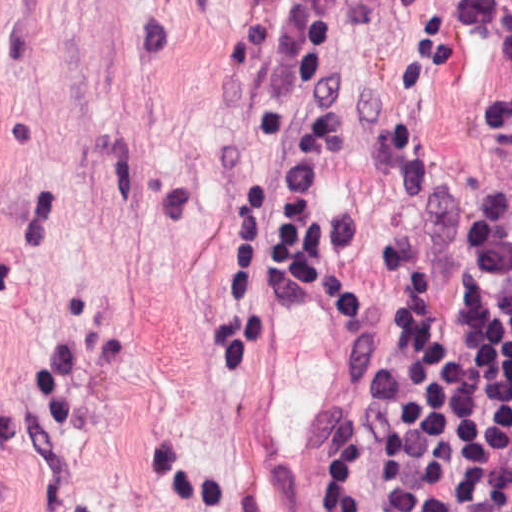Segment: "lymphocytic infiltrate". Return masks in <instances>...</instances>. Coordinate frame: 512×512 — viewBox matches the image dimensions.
<instances>
[{"label":"lymphocytic infiltrate","mask_w":512,"mask_h":512,"mask_svg":"<svg viewBox=\"0 0 512 512\" xmlns=\"http://www.w3.org/2000/svg\"><path fill=\"white\" fill-rule=\"evenodd\" d=\"M346 88L341 0H289L264 262L336 331L352 313V260L327 225L322 179ZM459 190L461 236L394 250L387 300L331 395L313 512L373 467L382 512H512V129L495 110Z\"/></svg>","instance_id":"obj_1"}]
</instances>
